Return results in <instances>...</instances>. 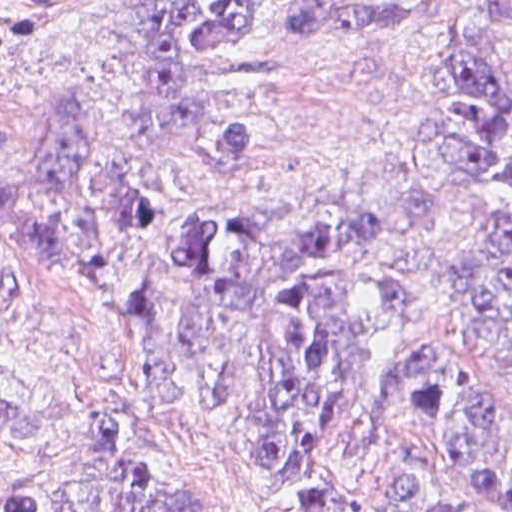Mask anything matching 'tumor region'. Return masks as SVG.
Masks as SVG:
<instances>
[{
	"label": "tumor region",
	"mask_w": 512,
	"mask_h": 512,
	"mask_svg": "<svg viewBox=\"0 0 512 512\" xmlns=\"http://www.w3.org/2000/svg\"><path fill=\"white\" fill-rule=\"evenodd\" d=\"M255 12L256 0H130L104 20L105 42L124 47L126 78L157 132L185 134L197 125L206 68L226 66L242 82L238 113L206 141L219 177L203 196H179L129 176L99 144L81 90L53 102L30 130L0 127V158L27 169L0 179V221L22 235L20 249L0 259V305L41 282L89 291L143 321V352L204 384L228 416L224 361L201 363L202 331L163 308L160 256L211 294L237 292L255 271L256 180L273 159L264 97L271 71L254 49ZM434 14L435 0L316 1L284 10L278 30L310 51L344 39L398 37ZM482 23L512 35V0ZM441 60L455 80V196L435 185L415 193L433 248L480 163L512 136V101L487 52L462 40ZM511 170L512 153L494 162L491 194ZM391 221L392 207L372 201L301 242L263 313L282 356L281 391L255 416L233 423L287 512H317L324 433L381 409L408 422L454 472L452 489L438 491L401 470L400 491L421 512H512V468L497 452L481 395L450 387L444 350L415 327L424 276L378 277L350 260L361 245L387 235ZM476 231L446 258L447 293ZM479 298L485 330L512 364V204ZM199 485L208 487L136 449L83 441L0 512H257Z\"/></svg>",
	"instance_id": "tumor-region-1"
}]
</instances>
